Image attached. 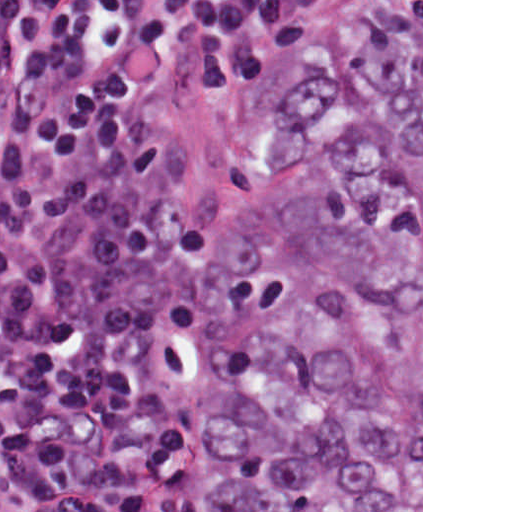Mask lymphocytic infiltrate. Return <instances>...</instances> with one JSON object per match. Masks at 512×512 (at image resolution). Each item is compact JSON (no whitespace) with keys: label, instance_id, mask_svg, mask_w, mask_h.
<instances>
[{"label":"lymphocytic infiltrate","instance_id":"lymphocytic-infiltrate-1","mask_svg":"<svg viewBox=\"0 0 512 512\" xmlns=\"http://www.w3.org/2000/svg\"><path fill=\"white\" fill-rule=\"evenodd\" d=\"M193 90L294 75V0H0V512H165L217 222L135 106L139 51Z\"/></svg>","mask_w":512,"mask_h":512}]
</instances>
